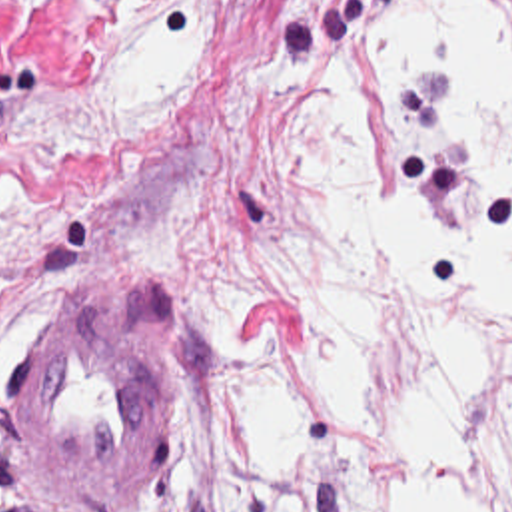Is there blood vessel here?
<instances>
[{
	"instance_id": "blood-vessel-1",
	"label": "blood vessel",
	"mask_w": 512,
	"mask_h": 512,
	"mask_svg": "<svg viewBox=\"0 0 512 512\" xmlns=\"http://www.w3.org/2000/svg\"><path fill=\"white\" fill-rule=\"evenodd\" d=\"M159 335L91 287H63L45 301L11 405L23 455L51 497L101 503L145 469L169 407Z\"/></svg>"
}]
</instances>
